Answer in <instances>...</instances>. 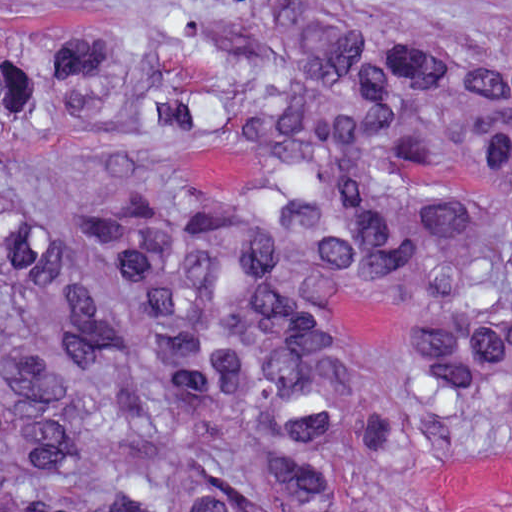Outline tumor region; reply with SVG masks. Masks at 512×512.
Masks as SVG:
<instances>
[{
	"label": "tumor region",
	"instance_id": "obj_1",
	"mask_svg": "<svg viewBox=\"0 0 512 512\" xmlns=\"http://www.w3.org/2000/svg\"><path fill=\"white\" fill-rule=\"evenodd\" d=\"M512 431V0L0 11V512H416Z\"/></svg>",
	"mask_w": 512,
	"mask_h": 512
}]
</instances>
